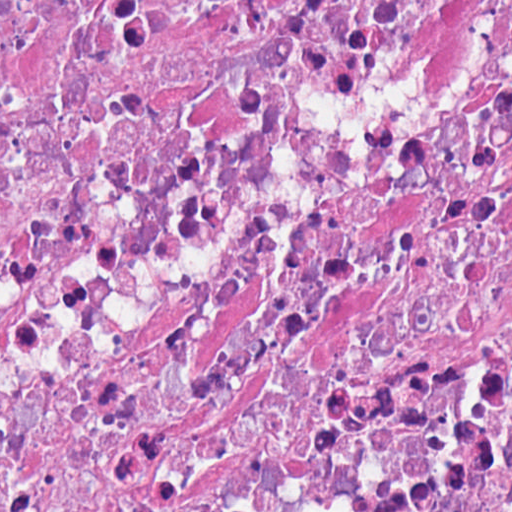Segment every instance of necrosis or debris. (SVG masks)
I'll return each instance as SVG.
<instances>
[{
  "instance_id": "1",
  "label": "necrosis or debris",
  "mask_w": 512,
  "mask_h": 512,
  "mask_svg": "<svg viewBox=\"0 0 512 512\" xmlns=\"http://www.w3.org/2000/svg\"><path fill=\"white\" fill-rule=\"evenodd\" d=\"M1 512H512V0H1Z\"/></svg>"
}]
</instances>
